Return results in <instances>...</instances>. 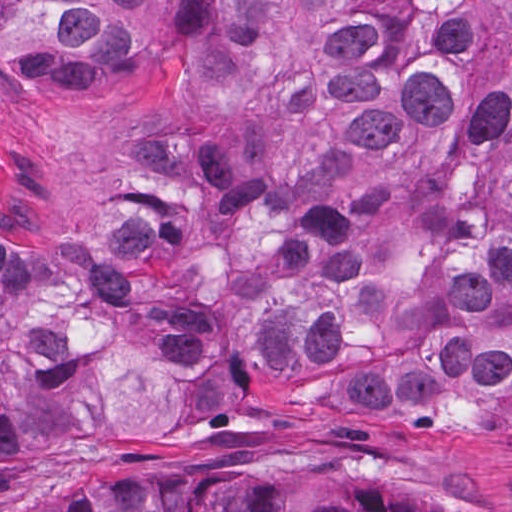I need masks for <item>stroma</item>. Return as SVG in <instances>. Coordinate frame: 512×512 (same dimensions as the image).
<instances>
[{
  "instance_id": "stroma-1",
  "label": "stroma",
  "mask_w": 512,
  "mask_h": 512,
  "mask_svg": "<svg viewBox=\"0 0 512 512\" xmlns=\"http://www.w3.org/2000/svg\"><path fill=\"white\" fill-rule=\"evenodd\" d=\"M141 76L118 47L104 87L43 90L0 56V252L16 280L14 325L58 335L77 364L60 452L76 440L0 466V512H68L196 473L381 489L424 512H512V388L473 413L303 392L232 402L104 331L79 303L73 281L102 233L105 170Z\"/></svg>"
}]
</instances>
